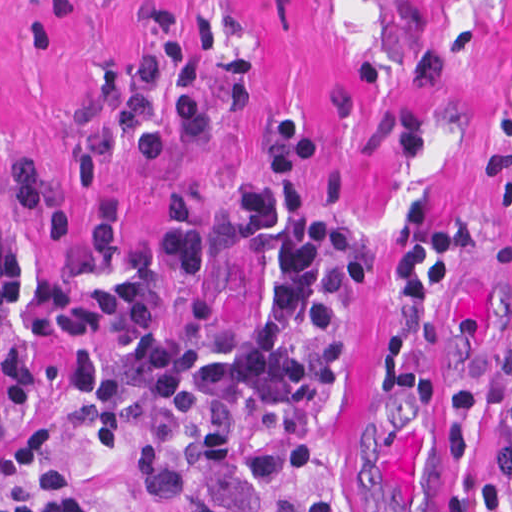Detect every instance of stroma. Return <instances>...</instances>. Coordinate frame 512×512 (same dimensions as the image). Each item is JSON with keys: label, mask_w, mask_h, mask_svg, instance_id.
I'll use <instances>...</instances> for the list:
<instances>
[{"label": "stroma", "mask_w": 512, "mask_h": 512, "mask_svg": "<svg viewBox=\"0 0 512 512\" xmlns=\"http://www.w3.org/2000/svg\"><path fill=\"white\" fill-rule=\"evenodd\" d=\"M170 1L200 104L217 102L219 67L243 58L247 107L204 122L175 155L144 163L122 153L72 190L99 71L137 59L147 0H0V172L34 163L62 205V235L51 243L30 212L10 213L25 294L0 315V495L19 443L42 430L60 442L81 499L103 512H164L135 467L67 415L61 358L82 348L110 356L115 333L49 338L38 295L47 275L88 255L100 194L120 192L129 204L122 250L190 193L208 278L248 342L271 282L238 244L239 189L282 179L312 210H357L375 274L342 288L348 374L311 417L305 464L261 486L265 499L427 512L455 490L464 512H485L495 411L512 388V0ZM280 113H294L322 144L298 170H280L271 156L266 130ZM412 192L483 223L481 245L436 308L410 306L394 283V215ZM30 493L50 512L46 486L32 482Z\"/></svg>", "instance_id": "stroma-1"}]
</instances>
